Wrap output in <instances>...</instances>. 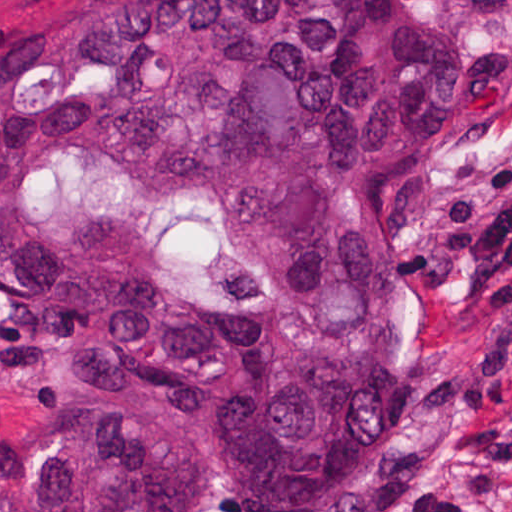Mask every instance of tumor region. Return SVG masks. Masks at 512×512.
Here are the masks:
<instances>
[{
  "instance_id": "tumor-region-1",
  "label": "tumor region",
  "mask_w": 512,
  "mask_h": 512,
  "mask_svg": "<svg viewBox=\"0 0 512 512\" xmlns=\"http://www.w3.org/2000/svg\"><path fill=\"white\" fill-rule=\"evenodd\" d=\"M512 85L410 0H119L0 36V512H344L404 416V179Z\"/></svg>"
}]
</instances>
